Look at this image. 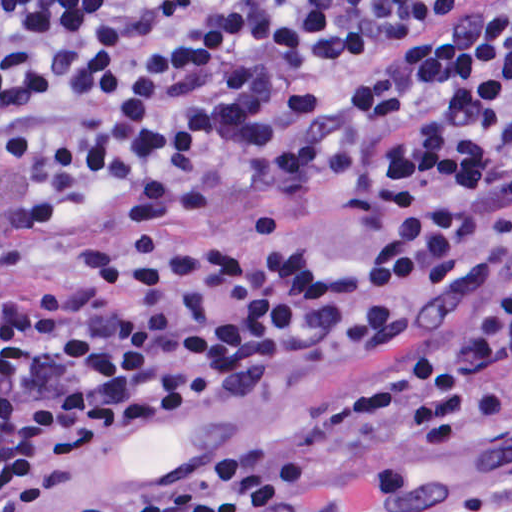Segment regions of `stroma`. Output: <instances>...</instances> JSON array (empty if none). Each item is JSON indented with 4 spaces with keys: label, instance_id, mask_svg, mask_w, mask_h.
<instances>
[{
    "label": "stroma",
    "instance_id": "stroma-1",
    "mask_svg": "<svg viewBox=\"0 0 512 512\" xmlns=\"http://www.w3.org/2000/svg\"><path fill=\"white\" fill-rule=\"evenodd\" d=\"M310 245L329 259L370 268V247L353 213L294 198L229 191L209 217L134 245L98 253H41L8 239L0 223V293L13 284L68 285L100 264L164 249ZM389 346L361 347L325 359L304 374L264 388H236L173 412L108 447L30 512H73L114 493L283 443L340 455L326 500L313 512H345L341 484L358 396ZM390 410L381 422L387 455L419 475L396 512H496L512 500V431L478 437L476 420L460 439L422 443Z\"/></svg>",
    "mask_w": 512,
    "mask_h": 512
}]
</instances>
